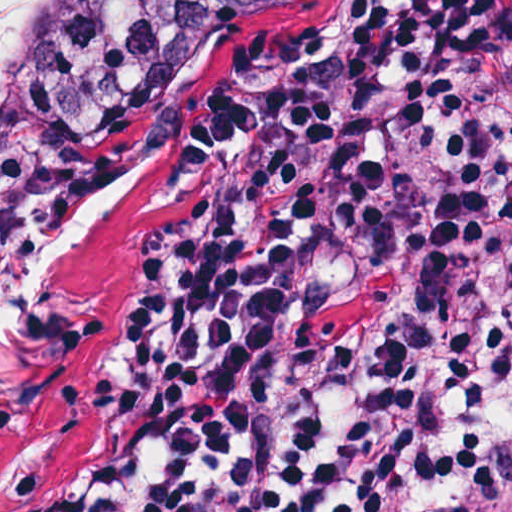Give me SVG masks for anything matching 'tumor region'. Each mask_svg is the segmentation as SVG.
Here are the masks:
<instances>
[{"mask_svg": "<svg viewBox=\"0 0 512 512\" xmlns=\"http://www.w3.org/2000/svg\"><path fill=\"white\" fill-rule=\"evenodd\" d=\"M333 1L102 0L43 92L0 129V279L115 186L183 100L256 44ZM406 15L357 68L385 50ZM283 198L278 180L214 216L184 250L264 231ZM128 375L78 466L107 439Z\"/></svg>", "mask_w": 512, "mask_h": 512, "instance_id": "e687c5a6", "label": "tumor region"}]
</instances>
